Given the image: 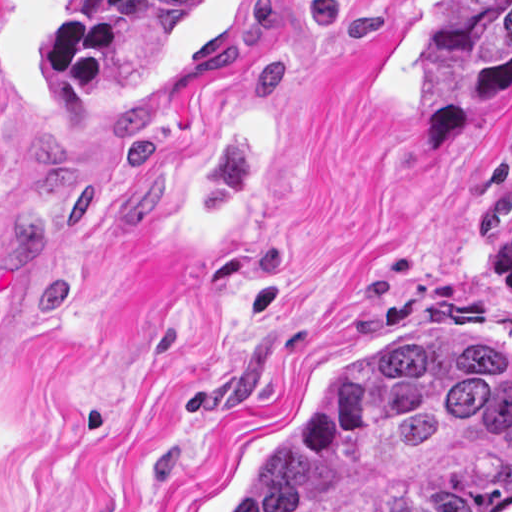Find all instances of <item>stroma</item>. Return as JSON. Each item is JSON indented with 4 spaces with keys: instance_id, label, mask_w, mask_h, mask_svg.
I'll list each match as a JSON object with an SVG mask.
<instances>
[{
    "instance_id": "1",
    "label": "stroma",
    "mask_w": 512,
    "mask_h": 512,
    "mask_svg": "<svg viewBox=\"0 0 512 512\" xmlns=\"http://www.w3.org/2000/svg\"><path fill=\"white\" fill-rule=\"evenodd\" d=\"M75 1L0 0V512H225L361 352L512 363V87L430 137L432 0H207L64 110Z\"/></svg>"
}]
</instances>
